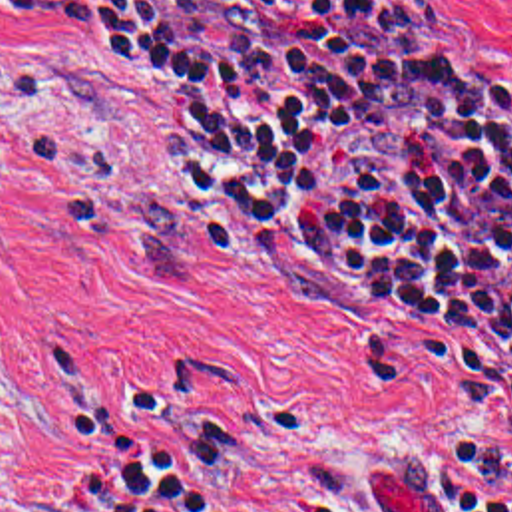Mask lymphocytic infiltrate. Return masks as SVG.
Returning <instances> with one entry per match:
<instances>
[{
    "label": "lymphocytic infiltrate",
    "instance_id": "lymphocytic-infiltrate-1",
    "mask_svg": "<svg viewBox=\"0 0 512 512\" xmlns=\"http://www.w3.org/2000/svg\"><path fill=\"white\" fill-rule=\"evenodd\" d=\"M121 53L203 186L300 288L495 346L512 413V119L424 0H14ZM444 512H512V457L434 445Z\"/></svg>",
    "mask_w": 512,
    "mask_h": 512
}]
</instances>
